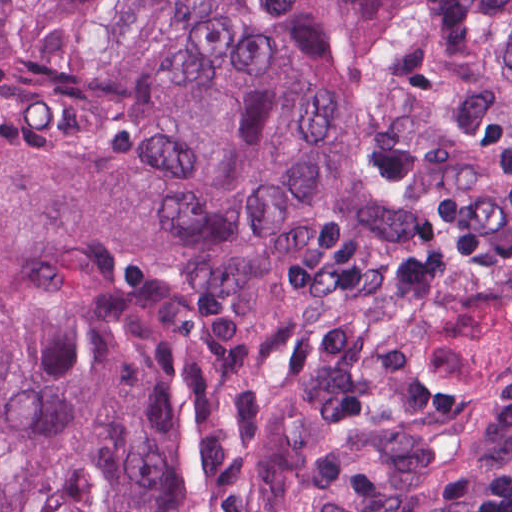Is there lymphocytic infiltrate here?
Here are the masks:
<instances>
[{"label":"lymphocytic infiltrate","mask_w":512,"mask_h":512,"mask_svg":"<svg viewBox=\"0 0 512 512\" xmlns=\"http://www.w3.org/2000/svg\"><path fill=\"white\" fill-rule=\"evenodd\" d=\"M512 389V351L499 371ZM394 512H512V466H442L427 472Z\"/></svg>","instance_id":"f902f5d3"}]
</instances>
